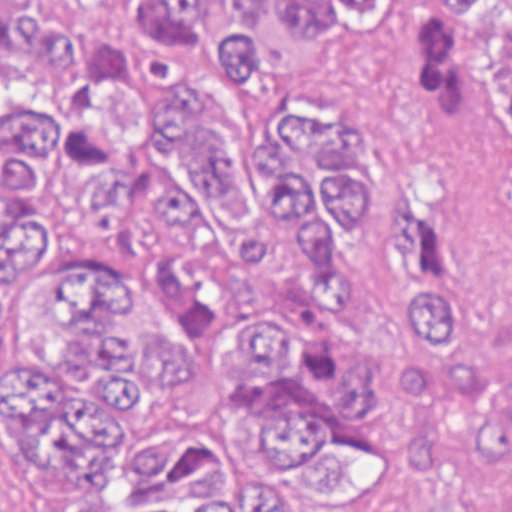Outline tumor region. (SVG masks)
Here are the masks:
<instances>
[{
    "mask_svg": "<svg viewBox=\"0 0 512 512\" xmlns=\"http://www.w3.org/2000/svg\"><path fill=\"white\" fill-rule=\"evenodd\" d=\"M392 0H0V185L125 442L138 512L342 499L374 446L350 244L383 143L265 87ZM423 122L512 172V0H431ZM384 309L407 512H512V298L445 197L397 185Z\"/></svg>",
    "mask_w": 512,
    "mask_h": 512,
    "instance_id": "tumor-region-1",
    "label": "tumor region"
}]
</instances>
